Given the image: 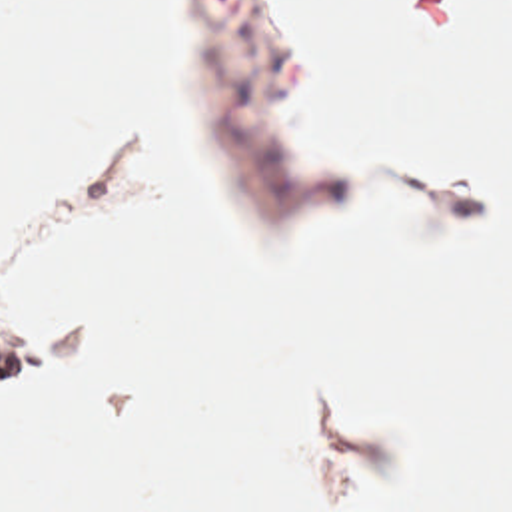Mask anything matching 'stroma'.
I'll list each match as a JSON object with an SVG mask.
<instances>
[{"mask_svg":"<svg viewBox=\"0 0 512 512\" xmlns=\"http://www.w3.org/2000/svg\"><path fill=\"white\" fill-rule=\"evenodd\" d=\"M197 25L229 123L249 247L259 265H283L319 193L337 187L349 163L339 145L301 135L297 77L263 41L257 15L235 0H197ZM50 343L42 321L0 307V398L30 390Z\"/></svg>","mask_w":512,"mask_h":512,"instance_id":"1","label":"stroma"}]
</instances>
